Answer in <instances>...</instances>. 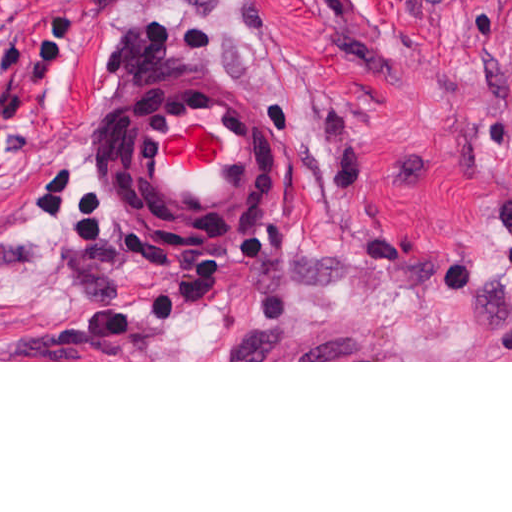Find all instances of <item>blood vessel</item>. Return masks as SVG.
I'll return each mask as SVG.
<instances>
[{
  "instance_id": "1",
  "label": "blood vessel",
  "mask_w": 512,
  "mask_h": 512,
  "mask_svg": "<svg viewBox=\"0 0 512 512\" xmlns=\"http://www.w3.org/2000/svg\"><path fill=\"white\" fill-rule=\"evenodd\" d=\"M278 176V111L247 65L188 71L139 105L120 156L133 219L205 262L264 230Z\"/></svg>"
}]
</instances>
